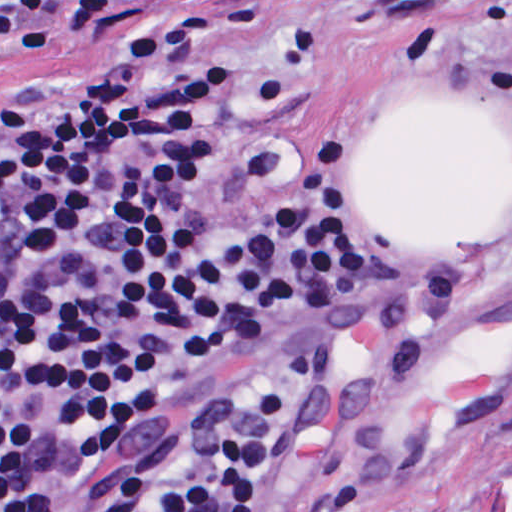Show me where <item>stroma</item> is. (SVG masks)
<instances>
[{"instance_id":"stroma-1","label":"stroma","mask_w":512,"mask_h":512,"mask_svg":"<svg viewBox=\"0 0 512 512\" xmlns=\"http://www.w3.org/2000/svg\"><path fill=\"white\" fill-rule=\"evenodd\" d=\"M85 28L0 64V110L87 76L181 17L242 25L198 208L266 145L334 136L379 162L399 313L290 372L279 439L244 512H512V0H104ZM378 290L276 313L180 378L117 448L46 415L52 473L90 485L237 409L336 339Z\"/></svg>"}]
</instances>
